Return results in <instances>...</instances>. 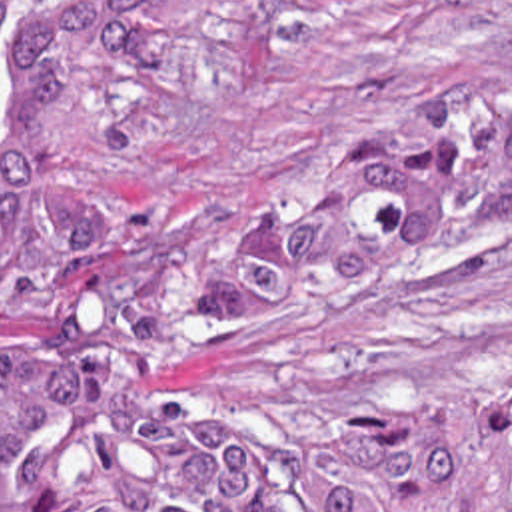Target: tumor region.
Returning a JSON list of instances; mask_svg holds the SVG:
<instances>
[{"label": "tumor region", "mask_w": 512, "mask_h": 512, "mask_svg": "<svg viewBox=\"0 0 512 512\" xmlns=\"http://www.w3.org/2000/svg\"><path fill=\"white\" fill-rule=\"evenodd\" d=\"M202 2L0 0V280L47 300L0 352V512H512V390L422 398L370 438L142 398L512 226V102L434 110L232 216L128 212L85 178L81 70Z\"/></svg>", "instance_id": "e687c5a6"}]
</instances>
